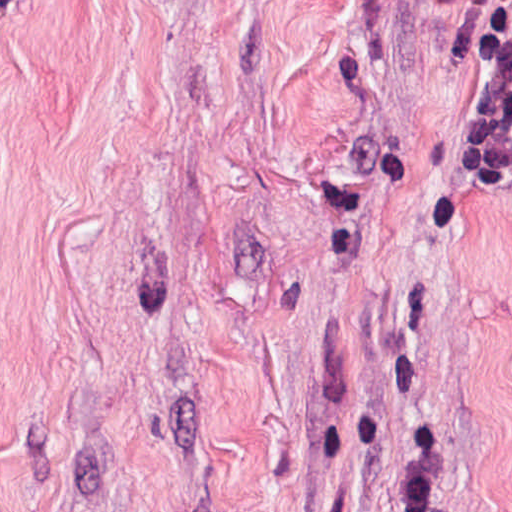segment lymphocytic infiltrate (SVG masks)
Returning a JSON list of instances; mask_svg holds the SVG:
<instances>
[{
  "instance_id": "f902f5d3",
  "label": "lymphocytic infiltrate",
  "mask_w": 512,
  "mask_h": 512,
  "mask_svg": "<svg viewBox=\"0 0 512 512\" xmlns=\"http://www.w3.org/2000/svg\"><path fill=\"white\" fill-rule=\"evenodd\" d=\"M472 163L512 165V0H494V46L481 79ZM443 420L422 416L412 428L401 464L404 512H440Z\"/></svg>"
}]
</instances>
